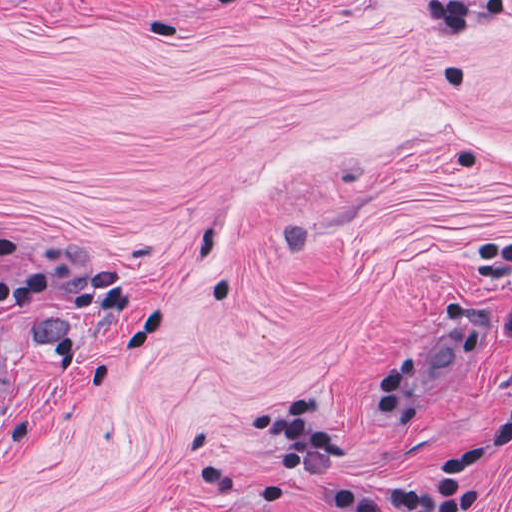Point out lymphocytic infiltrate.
<instances>
[{
    "label": "lymphocytic infiltrate",
    "mask_w": 512,
    "mask_h": 512,
    "mask_svg": "<svg viewBox=\"0 0 512 512\" xmlns=\"http://www.w3.org/2000/svg\"><path fill=\"white\" fill-rule=\"evenodd\" d=\"M488 252L505 262L510 273L504 329L512 338V239L496 237ZM374 398L396 421L419 417L407 374L387 365ZM253 427L272 443V465L279 476L293 483L315 481L339 512H484L490 498L481 479L484 468L512 453V400L503 416L416 484L366 486L340 474L335 466L351 443L326 425L324 403L317 397H284L262 405Z\"/></svg>",
    "instance_id": "lymphocytic-infiltrate-1"
}]
</instances>
